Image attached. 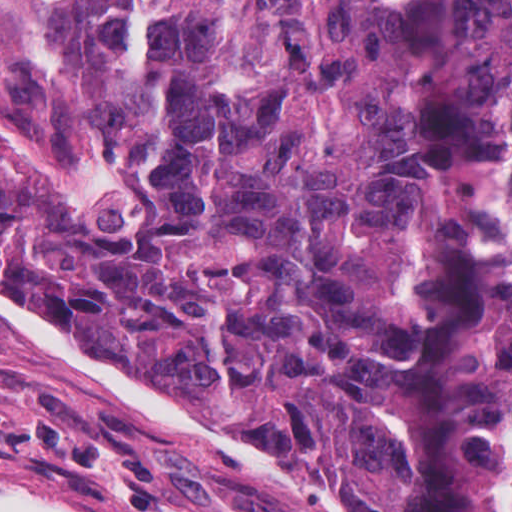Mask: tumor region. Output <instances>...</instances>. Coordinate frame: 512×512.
Masks as SVG:
<instances>
[{
	"instance_id": "tumor-region-1",
	"label": "tumor region",
	"mask_w": 512,
	"mask_h": 512,
	"mask_svg": "<svg viewBox=\"0 0 512 512\" xmlns=\"http://www.w3.org/2000/svg\"><path fill=\"white\" fill-rule=\"evenodd\" d=\"M126 177L0 117V284L255 410L349 512H512V0H76Z\"/></svg>"
}]
</instances>
